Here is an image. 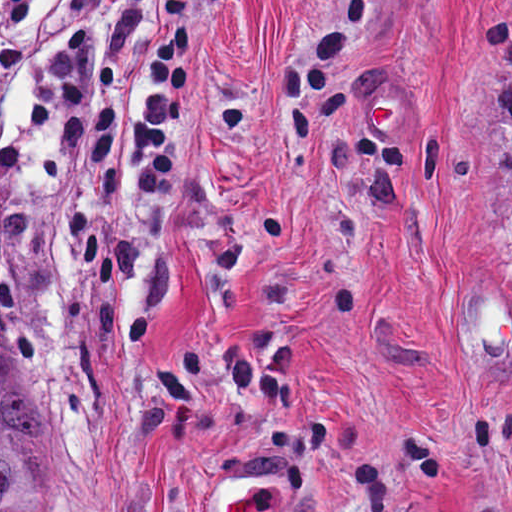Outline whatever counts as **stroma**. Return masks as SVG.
Returning <instances> with one entry per match:
<instances>
[{
    "label": "stroma",
    "instance_id": "35a3bbf8",
    "mask_svg": "<svg viewBox=\"0 0 512 512\" xmlns=\"http://www.w3.org/2000/svg\"><path fill=\"white\" fill-rule=\"evenodd\" d=\"M40 0L0 126V362L42 512H512V0H189L176 173L126 133L168 0H101L110 164ZM379 87L419 102L378 140Z\"/></svg>",
    "mask_w": 512,
    "mask_h": 512
}]
</instances>
